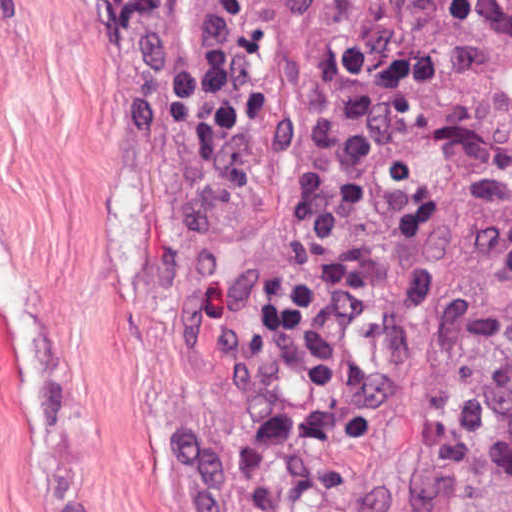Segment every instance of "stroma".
<instances>
[{"label": "stroma", "instance_id": "stroma-1", "mask_svg": "<svg viewBox=\"0 0 512 512\" xmlns=\"http://www.w3.org/2000/svg\"><path fill=\"white\" fill-rule=\"evenodd\" d=\"M415 0H319L257 143L232 145L129 45L118 0H0V512H242L263 421L259 293L345 84ZM512 0L446 136L354 252L366 387L312 512H459L512 489L500 332L512 232Z\"/></svg>", "mask_w": 512, "mask_h": 512}]
</instances>
